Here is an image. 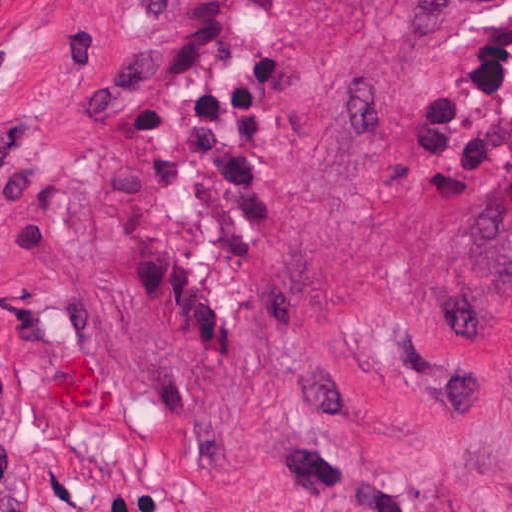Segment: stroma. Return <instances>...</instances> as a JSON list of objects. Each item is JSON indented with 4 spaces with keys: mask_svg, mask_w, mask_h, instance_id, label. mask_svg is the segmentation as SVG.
Segmentation results:
<instances>
[{
    "mask_svg": "<svg viewBox=\"0 0 512 512\" xmlns=\"http://www.w3.org/2000/svg\"><path fill=\"white\" fill-rule=\"evenodd\" d=\"M0 512H512V0H0Z\"/></svg>",
    "mask_w": 512,
    "mask_h": 512,
    "instance_id": "1",
    "label": "stroma"
}]
</instances>
